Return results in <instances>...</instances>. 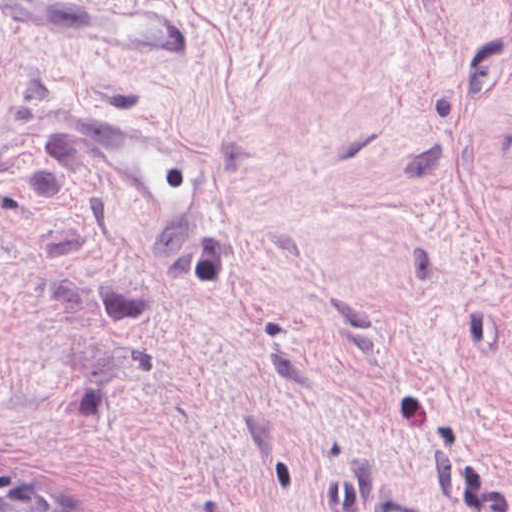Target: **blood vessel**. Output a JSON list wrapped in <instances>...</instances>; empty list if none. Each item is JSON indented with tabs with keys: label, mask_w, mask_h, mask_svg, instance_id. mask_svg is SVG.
Returning <instances> with one entry per match:
<instances>
[{
	"label": "blood vessel",
	"mask_w": 512,
	"mask_h": 512,
	"mask_svg": "<svg viewBox=\"0 0 512 512\" xmlns=\"http://www.w3.org/2000/svg\"><path fill=\"white\" fill-rule=\"evenodd\" d=\"M0 14L17 32L84 58L193 59L188 16L161 1L0 0ZM56 110L67 134L120 173L153 243L185 236L215 183V155L195 135L106 106ZM402 498L384 486L371 489L365 512H422Z\"/></svg>",
	"instance_id": "blood-vessel-1"
}]
</instances>
